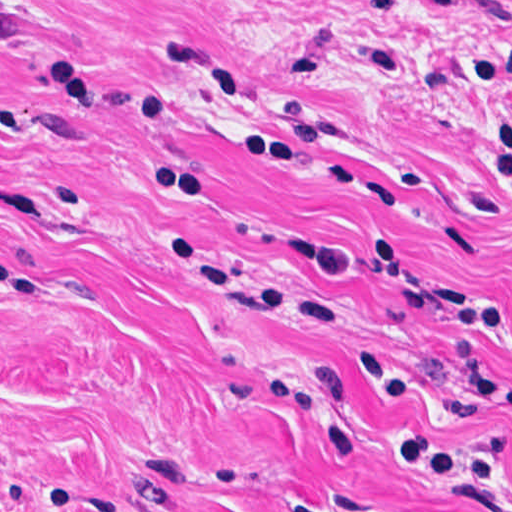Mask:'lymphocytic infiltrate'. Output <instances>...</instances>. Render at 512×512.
Instances as JSON below:
<instances>
[{"mask_svg":"<svg viewBox=\"0 0 512 512\" xmlns=\"http://www.w3.org/2000/svg\"><path fill=\"white\" fill-rule=\"evenodd\" d=\"M407 462L497 512H512V476L456 444L416 433V455ZM293 508L295 512H344L309 499Z\"/></svg>","mask_w":512,"mask_h":512,"instance_id":"f902f5d3","label":"lymphocytic infiltrate"}]
</instances>
